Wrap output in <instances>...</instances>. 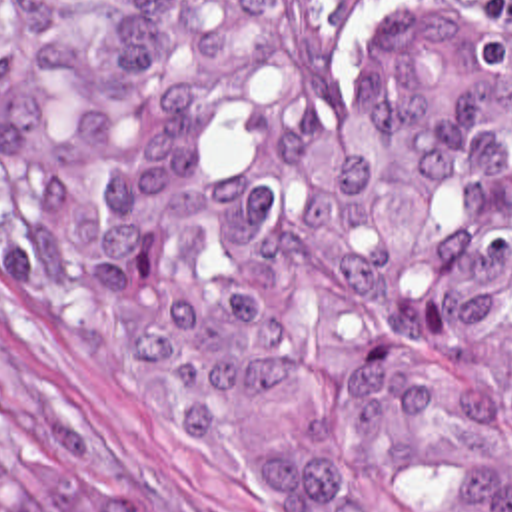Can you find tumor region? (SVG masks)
<instances>
[{
	"instance_id": "tumor-region-1",
	"label": "tumor region",
	"mask_w": 512,
	"mask_h": 512,
	"mask_svg": "<svg viewBox=\"0 0 512 512\" xmlns=\"http://www.w3.org/2000/svg\"><path fill=\"white\" fill-rule=\"evenodd\" d=\"M0 0V274L304 512H512V0ZM0 512H152L0 390Z\"/></svg>"
}]
</instances>
